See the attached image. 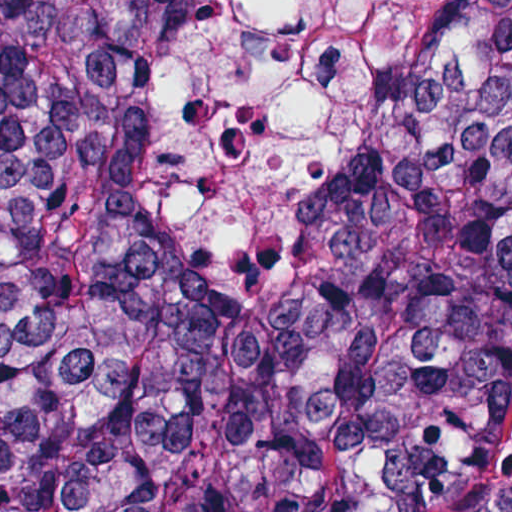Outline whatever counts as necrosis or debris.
<instances>
[{"mask_svg": "<svg viewBox=\"0 0 512 512\" xmlns=\"http://www.w3.org/2000/svg\"><path fill=\"white\" fill-rule=\"evenodd\" d=\"M466 0H218L145 128L146 206L193 256L288 259Z\"/></svg>", "mask_w": 512, "mask_h": 512, "instance_id": "4bbe7bcc", "label": "necrosis or debris"}]
</instances>
